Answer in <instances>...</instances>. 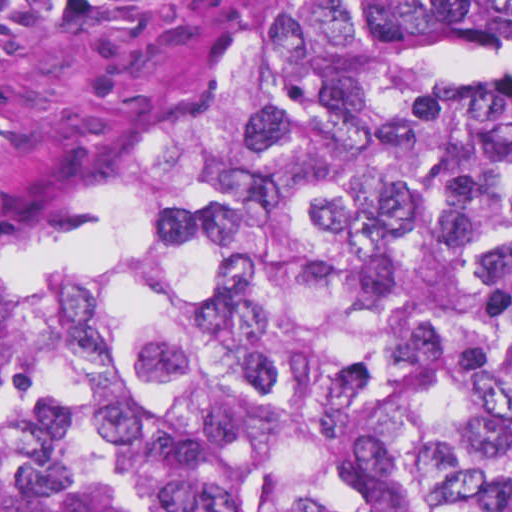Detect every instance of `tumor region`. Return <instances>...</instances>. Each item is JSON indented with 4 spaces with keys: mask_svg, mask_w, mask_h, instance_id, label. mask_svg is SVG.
<instances>
[{
    "mask_svg": "<svg viewBox=\"0 0 512 512\" xmlns=\"http://www.w3.org/2000/svg\"><path fill=\"white\" fill-rule=\"evenodd\" d=\"M0 512H512V0H282L3 218Z\"/></svg>",
    "mask_w": 512,
    "mask_h": 512,
    "instance_id": "1",
    "label": "tumor region"
}]
</instances>
